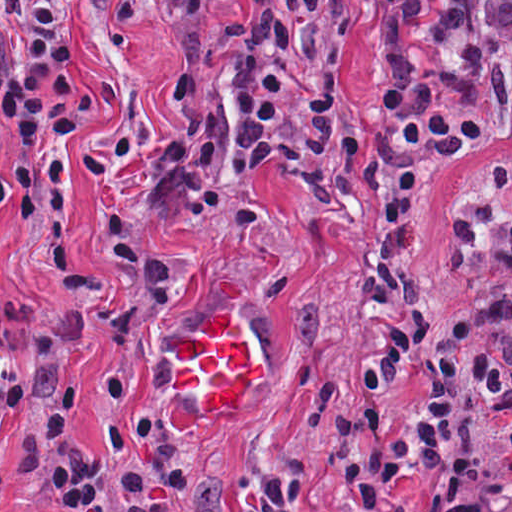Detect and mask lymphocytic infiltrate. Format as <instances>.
<instances>
[{
  "mask_svg": "<svg viewBox=\"0 0 512 512\" xmlns=\"http://www.w3.org/2000/svg\"><path fill=\"white\" fill-rule=\"evenodd\" d=\"M85 99L64 14L0 0V137Z\"/></svg>",
  "mask_w": 512,
  "mask_h": 512,
  "instance_id": "obj_1",
  "label": "lymphocytic infiltrate"
}]
</instances>
